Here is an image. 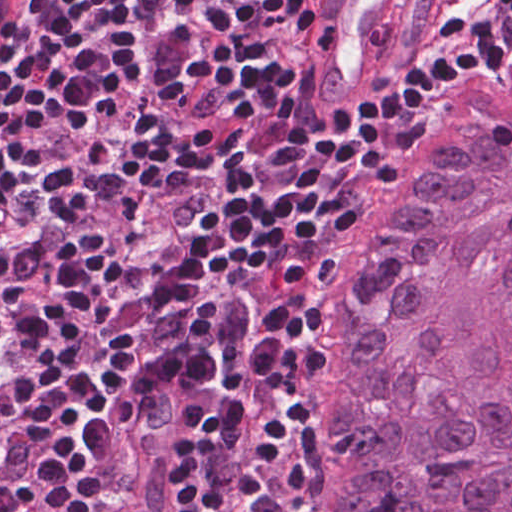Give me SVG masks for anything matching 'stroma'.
Wrapping results in <instances>:
<instances>
[{
    "label": "stroma",
    "mask_w": 512,
    "mask_h": 512,
    "mask_svg": "<svg viewBox=\"0 0 512 512\" xmlns=\"http://www.w3.org/2000/svg\"><path fill=\"white\" fill-rule=\"evenodd\" d=\"M328 1L329 0H324V9ZM452 1L454 0H400V13L398 16V37L395 49L391 54L390 58L388 59V61L386 62L385 66L383 67V71L381 72L380 76L374 81V83L364 92V94L358 100L365 98L373 93H376L394 84L406 63L420 47L425 35L434 27L438 13L448 3ZM2 60L3 58L0 60V64ZM500 71H512V60L506 62L499 68L489 73H495ZM472 80L464 81L426 95V97L418 106L415 113L403 127L398 156L409 143V141L414 137L423 121L451 93H453L454 91L461 88L462 86H464L465 84ZM308 92L311 103V109L313 112L327 115L333 111H345L329 110L320 102L313 87L310 69L308 75ZM398 156L396 157V159L398 158ZM393 164L384 174L383 178L389 172ZM380 183L367 184L364 195L356 211L355 217L350 225L349 237L365 202L368 200V198L371 196V194L374 192V190L378 187ZM163 382L166 381H153L152 383L148 384L146 387H144L146 394L149 393V391L154 387L155 384ZM172 385L176 387L182 394L181 390L178 388L177 385ZM142 390L135 394L134 397L126 401L122 415L117 423V438L106 493V512L128 511L129 496L132 488L133 479V442L135 410L139 398L141 396ZM182 512H194V464L187 452L186 401L184 501Z\"/></svg>",
    "instance_id": "obj_1"
}]
</instances>
